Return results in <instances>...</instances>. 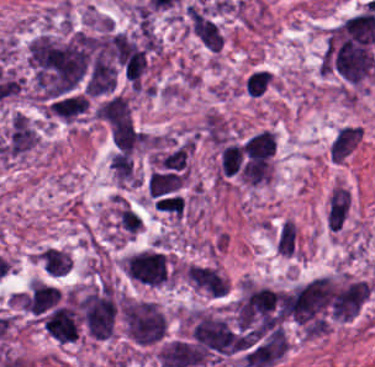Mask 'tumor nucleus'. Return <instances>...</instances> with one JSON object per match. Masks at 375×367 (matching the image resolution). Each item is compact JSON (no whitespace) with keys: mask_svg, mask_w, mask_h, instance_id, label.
<instances>
[{"mask_svg":"<svg viewBox=\"0 0 375 367\" xmlns=\"http://www.w3.org/2000/svg\"><path fill=\"white\" fill-rule=\"evenodd\" d=\"M121 270L132 281L149 286L168 283L174 275L166 253L152 248H144L123 257Z\"/></svg>","mask_w":375,"mask_h":367,"instance_id":"tumor-nucleus-2","label":"tumor nucleus"},{"mask_svg":"<svg viewBox=\"0 0 375 367\" xmlns=\"http://www.w3.org/2000/svg\"><path fill=\"white\" fill-rule=\"evenodd\" d=\"M348 205L347 190L336 184L327 199L326 226L329 230L339 229Z\"/></svg>","mask_w":375,"mask_h":367,"instance_id":"tumor-nucleus-7","label":"tumor nucleus"},{"mask_svg":"<svg viewBox=\"0 0 375 367\" xmlns=\"http://www.w3.org/2000/svg\"><path fill=\"white\" fill-rule=\"evenodd\" d=\"M59 300L58 288L37 280H30L20 297L21 306L37 315L52 309Z\"/></svg>","mask_w":375,"mask_h":367,"instance_id":"tumor-nucleus-5","label":"tumor nucleus"},{"mask_svg":"<svg viewBox=\"0 0 375 367\" xmlns=\"http://www.w3.org/2000/svg\"><path fill=\"white\" fill-rule=\"evenodd\" d=\"M360 134L359 127L350 125L341 126L328 145L331 161L343 162L358 143Z\"/></svg>","mask_w":375,"mask_h":367,"instance_id":"tumor-nucleus-6","label":"tumor nucleus"},{"mask_svg":"<svg viewBox=\"0 0 375 367\" xmlns=\"http://www.w3.org/2000/svg\"><path fill=\"white\" fill-rule=\"evenodd\" d=\"M272 84L271 77L263 69H255L244 79V93L248 96L259 97Z\"/></svg>","mask_w":375,"mask_h":367,"instance_id":"tumor-nucleus-9","label":"tumor nucleus"},{"mask_svg":"<svg viewBox=\"0 0 375 367\" xmlns=\"http://www.w3.org/2000/svg\"><path fill=\"white\" fill-rule=\"evenodd\" d=\"M276 253L286 257L296 256L297 230L290 220H283L274 235Z\"/></svg>","mask_w":375,"mask_h":367,"instance_id":"tumor-nucleus-8","label":"tumor nucleus"},{"mask_svg":"<svg viewBox=\"0 0 375 367\" xmlns=\"http://www.w3.org/2000/svg\"><path fill=\"white\" fill-rule=\"evenodd\" d=\"M118 317L128 341L147 347L164 337L165 316L152 300L126 297L118 303Z\"/></svg>","mask_w":375,"mask_h":367,"instance_id":"tumor-nucleus-1","label":"tumor nucleus"},{"mask_svg":"<svg viewBox=\"0 0 375 367\" xmlns=\"http://www.w3.org/2000/svg\"><path fill=\"white\" fill-rule=\"evenodd\" d=\"M185 19L201 45L217 51L221 48L223 37L216 5L199 0L186 8Z\"/></svg>","mask_w":375,"mask_h":367,"instance_id":"tumor-nucleus-3","label":"tumor nucleus"},{"mask_svg":"<svg viewBox=\"0 0 375 367\" xmlns=\"http://www.w3.org/2000/svg\"><path fill=\"white\" fill-rule=\"evenodd\" d=\"M181 274L190 288L211 298H221L223 277L214 266L188 263Z\"/></svg>","mask_w":375,"mask_h":367,"instance_id":"tumor-nucleus-4","label":"tumor nucleus"}]
</instances>
